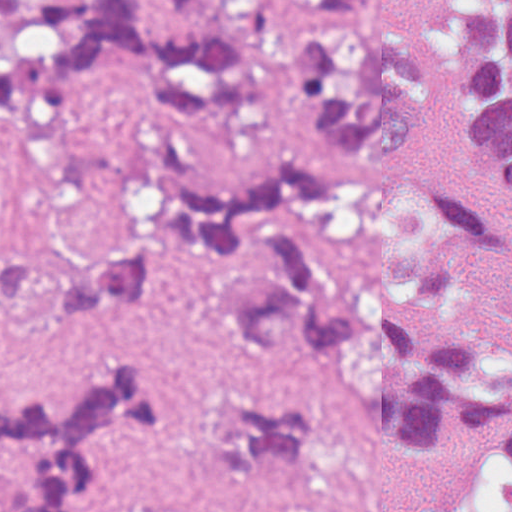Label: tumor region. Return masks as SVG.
<instances>
[{
  "instance_id": "tumor-region-1",
  "label": "tumor region",
  "mask_w": 512,
  "mask_h": 512,
  "mask_svg": "<svg viewBox=\"0 0 512 512\" xmlns=\"http://www.w3.org/2000/svg\"><path fill=\"white\" fill-rule=\"evenodd\" d=\"M293 90L290 131L238 170H168L119 240L34 262L0 228V311L97 317L203 262L208 308L249 361L313 336L381 428L470 444L446 512H512V0H453L420 44L381 0H0V128L64 126L125 94L215 114ZM187 410L148 362L88 369L57 397L0 376V512H296L325 404L240 413L206 505H134L112 447Z\"/></svg>"
}]
</instances>
